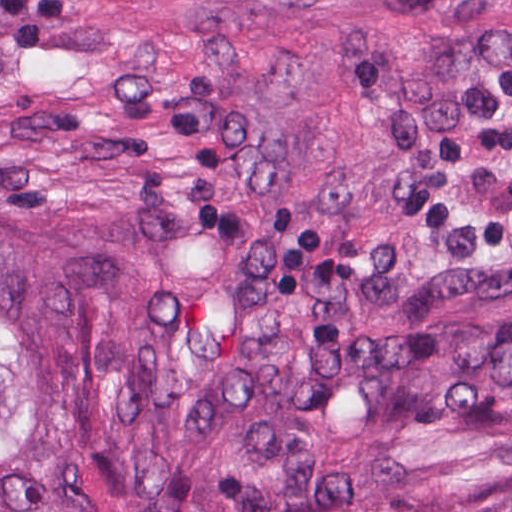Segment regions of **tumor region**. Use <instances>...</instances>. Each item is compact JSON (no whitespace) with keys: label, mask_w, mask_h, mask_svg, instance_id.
I'll use <instances>...</instances> for the list:
<instances>
[{"label":"tumor region","mask_w":512,"mask_h":512,"mask_svg":"<svg viewBox=\"0 0 512 512\" xmlns=\"http://www.w3.org/2000/svg\"><path fill=\"white\" fill-rule=\"evenodd\" d=\"M0 512H512V0H0Z\"/></svg>","instance_id":"obj_1"}]
</instances>
